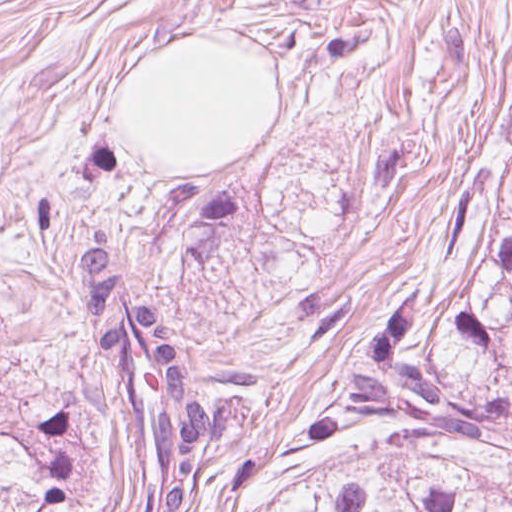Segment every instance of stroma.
Here are the masks:
<instances>
[{
  "label": "stroma",
  "mask_w": 512,
  "mask_h": 512,
  "mask_svg": "<svg viewBox=\"0 0 512 512\" xmlns=\"http://www.w3.org/2000/svg\"><path fill=\"white\" fill-rule=\"evenodd\" d=\"M180 35L260 48L275 77V131L206 169H162L117 120L133 61ZM511 95L512 0H0V387L67 403L40 512H127L82 230L107 227L206 365L256 369L246 436L197 472L196 512H230L252 448H288L430 281Z\"/></svg>",
  "instance_id": "35a3bbf8"
}]
</instances>
